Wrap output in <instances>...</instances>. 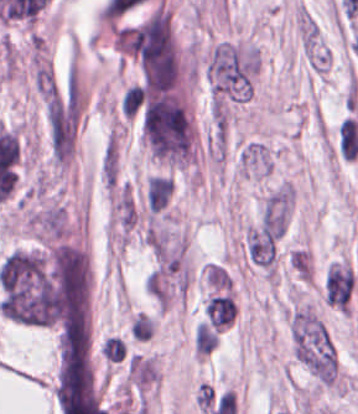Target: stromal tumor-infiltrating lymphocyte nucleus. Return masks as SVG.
Listing matches in <instances>:
<instances>
[{
  "label": "stromal tumor-infiltrating lymphocyte nucleus",
  "mask_w": 358,
  "mask_h": 414,
  "mask_svg": "<svg viewBox=\"0 0 358 414\" xmlns=\"http://www.w3.org/2000/svg\"><path fill=\"white\" fill-rule=\"evenodd\" d=\"M144 97V89L139 83H131L124 90L120 98V109L122 115L128 119H132L142 104Z\"/></svg>",
  "instance_id": "obj_1"
},
{
  "label": "stromal tumor-infiltrating lymphocyte nucleus",
  "mask_w": 358,
  "mask_h": 414,
  "mask_svg": "<svg viewBox=\"0 0 358 414\" xmlns=\"http://www.w3.org/2000/svg\"><path fill=\"white\" fill-rule=\"evenodd\" d=\"M100 350L106 362L123 359L127 353L126 342L116 335H109L102 340Z\"/></svg>",
  "instance_id": "obj_2"
}]
</instances>
